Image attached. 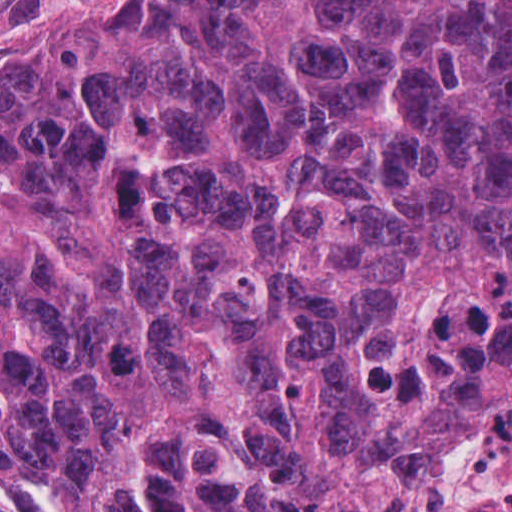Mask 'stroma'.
Returning a JSON list of instances; mask_svg holds the SVG:
<instances>
[{"instance_id": "35a3bbf8", "label": "stroma", "mask_w": 512, "mask_h": 512, "mask_svg": "<svg viewBox=\"0 0 512 512\" xmlns=\"http://www.w3.org/2000/svg\"><path fill=\"white\" fill-rule=\"evenodd\" d=\"M111 0H0V56L27 36L51 26L78 8Z\"/></svg>"}]
</instances>
